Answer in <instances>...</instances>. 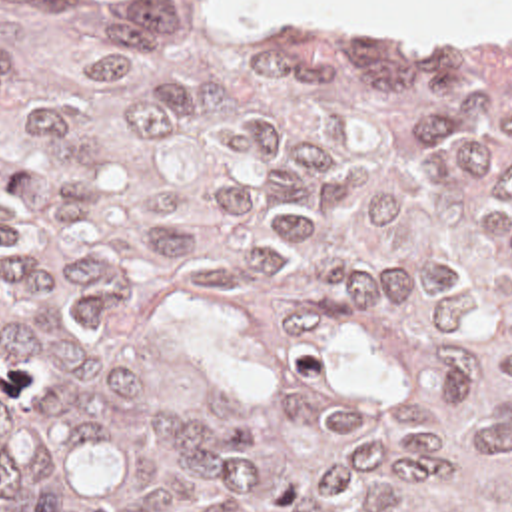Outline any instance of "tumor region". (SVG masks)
Listing matches in <instances>:
<instances>
[{"label":"tumor region","instance_id":"1","mask_svg":"<svg viewBox=\"0 0 512 512\" xmlns=\"http://www.w3.org/2000/svg\"><path fill=\"white\" fill-rule=\"evenodd\" d=\"M0 512H512V43L0 0Z\"/></svg>","mask_w":512,"mask_h":512}]
</instances>
